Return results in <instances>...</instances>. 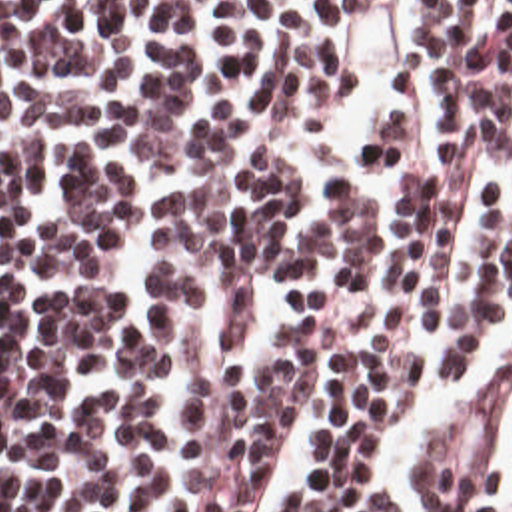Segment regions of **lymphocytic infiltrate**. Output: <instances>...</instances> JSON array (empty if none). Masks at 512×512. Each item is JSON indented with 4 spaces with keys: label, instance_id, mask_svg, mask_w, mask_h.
<instances>
[{
    "label": "lymphocytic infiltrate",
    "instance_id": "1",
    "mask_svg": "<svg viewBox=\"0 0 512 512\" xmlns=\"http://www.w3.org/2000/svg\"><path fill=\"white\" fill-rule=\"evenodd\" d=\"M373 1H0V512H247L309 402L275 512H391L385 440L512 306V0L419 1L437 172L413 78L363 150L395 244L347 174L289 234L267 134L339 110ZM497 466L477 392L425 512H497Z\"/></svg>",
    "mask_w": 512,
    "mask_h": 512
}]
</instances>
